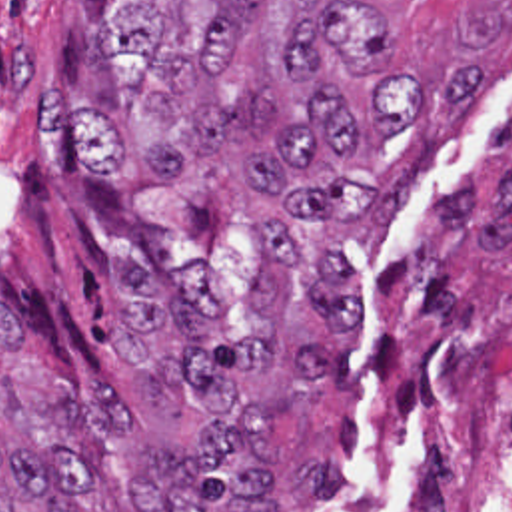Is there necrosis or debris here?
Segmentation results:
<instances>
[{
    "instance_id": "1",
    "label": "necrosis or debris",
    "mask_w": 512,
    "mask_h": 512,
    "mask_svg": "<svg viewBox=\"0 0 512 512\" xmlns=\"http://www.w3.org/2000/svg\"><path fill=\"white\" fill-rule=\"evenodd\" d=\"M387 512H512V342L443 340L373 434Z\"/></svg>"
}]
</instances>
